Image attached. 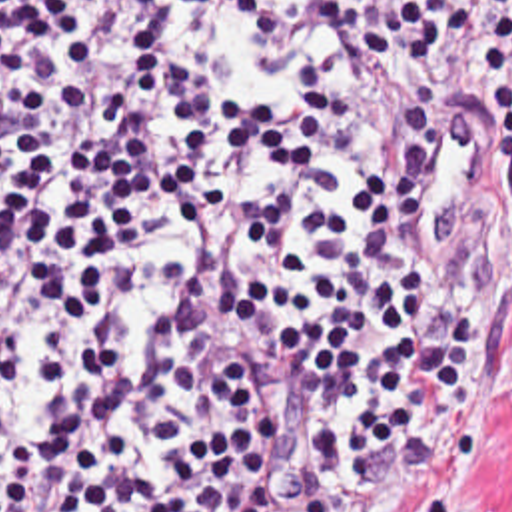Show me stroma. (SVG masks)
Returning a JSON list of instances; mask_svg holds the SVG:
<instances>
[{
    "label": "stroma",
    "instance_id": "35a3bbf8",
    "mask_svg": "<svg viewBox=\"0 0 512 512\" xmlns=\"http://www.w3.org/2000/svg\"><path fill=\"white\" fill-rule=\"evenodd\" d=\"M450 104L456 148L429 208V264L478 338V410L434 406V479L387 456L367 495L343 512H512V192L490 132L462 118L454 76Z\"/></svg>",
    "mask_w": 512,
    "mask_h": 512
}]
</instances>
